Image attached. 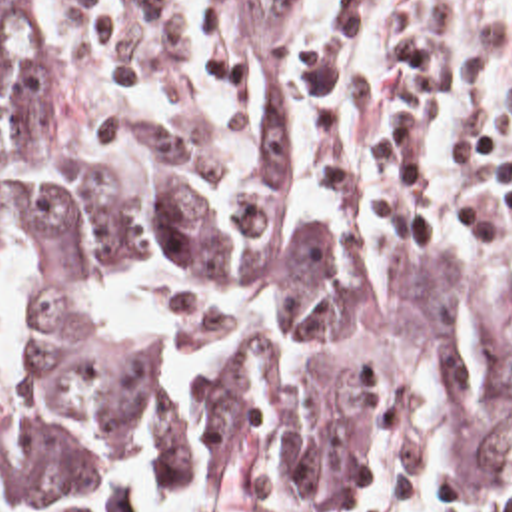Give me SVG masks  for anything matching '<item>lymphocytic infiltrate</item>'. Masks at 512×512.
<instances>
[{
	"instance_id": "lymphocytic-infiltrate-1",
	"label": "lymphocytic infiltrate",
	"mask_w": 512,
	"mask_h": 512,
	"mask_svg": "<svg viewBox=\"0 0 512 512\" xmlns=\"http://www.w3.org/2000/svg\"><path fill=\"white\" fill-rule=\"evenodd\" d=\"M505 49L493 0H335L327 43L309 37L315 189L377 231L512 271V157L485 129ZM503 93L512 119V75ZM435 512H512V492Z\"/></svg>"
}]
</instances>
